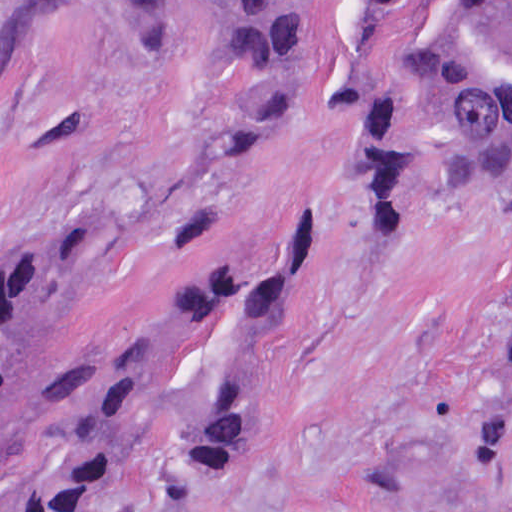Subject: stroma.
Segmentation results:
<instances>
[{
  "label": "stroma",
  "instance_id": "35a3bbf8",
  "mask_svg": "<svg viewBox=\"0 0 512 512\" xmlns=\"http://www.w3.org/2000/svg\"><path fill=\"white\" fill-rule=\"evenodd\" d=\"M222 0H154L150 31L87 0L0 71V277L47 229L93 228L59 306L53 384L0 512H58L97 397L186 278L228 240L261 263L308 212L317 256L263 312L192 337L141 446L163 454L214 374H270L255 422L179 512H512V146L473 169L446 105L355 0L314 11L280 59L228 58ZM103 287L117 248L176 219Z\"/></svg>",
  "mask_w": 512,
  "mask_h": 512
}]
</instances>
